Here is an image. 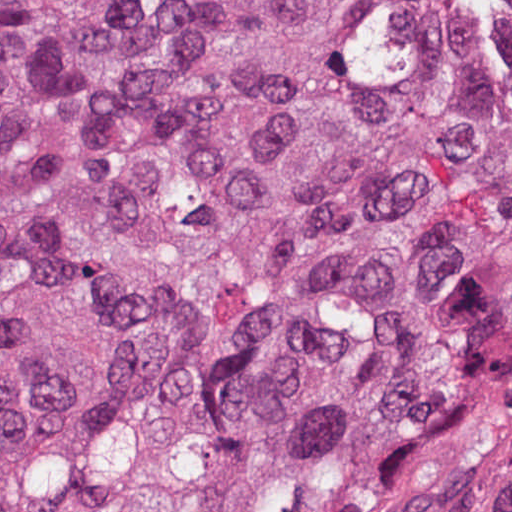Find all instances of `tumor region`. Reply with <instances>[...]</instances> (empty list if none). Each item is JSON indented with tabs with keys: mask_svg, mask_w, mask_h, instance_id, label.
<instances>
[{
	"mask_svg": "<svg viewBox=\"0 0 512 512\" xmlns=\"http://www.w3.org/2000/svg\"><path fill=\"white\" fill-rule=\"evenodd\" d=\"M0 512H512V0H0Z\"/></svg>",
	"mask_w": 512,
	"mask_h": 512,
	"instance_id": "e687c5a6",
	"label": "tumor region"
}]
</instances>
